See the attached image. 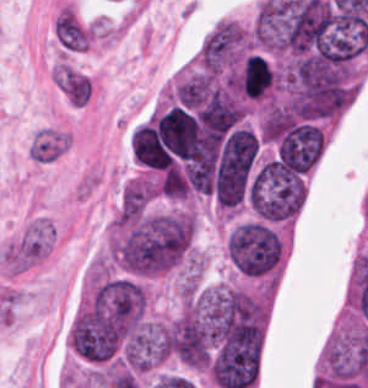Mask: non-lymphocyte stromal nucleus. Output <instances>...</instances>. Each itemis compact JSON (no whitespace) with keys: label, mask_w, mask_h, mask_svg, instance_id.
Masks as SVG:
<instances>
[{"label":"non-lymphocyte stromal nucleus","mask_w":368,"mask_h":388,"mask_svg":"<svg viewBox=\"0 0 368 388\" xmlns=\"http://www.w3.org/2000/svg\"><path fill=\"white\" fill-rule=\"evenodd\" d=\"M52 225L35 219L1 252L3 266L12 273H21L46 256L52 247Z\"/></svg>","instance_id":"dd21d789"},{"label":"non-lymphocyte stromal nucleus","mask_w":368,"mask_h":388,"mask_svg":"<svg viewBox=\"0 0 368 388\" xmlns=\"http://www.w3.org/2000/svg\"><path fill=\"white\" fill-rule=\"evenodd\" d=\"M57 80L65 95L74 104H85L92 94L89 75L65 64L56 65Z\"/></svg>","instance_id":"a72fc3eb"},{"label":"non-lymphocyte stromal nucleus","mask_w":368,"mask_h":388,"mask_svg":"<svg viewBox=\"0 0 368 388\" xmlns=\"http://www.w3.org/2000/svg\"><path fill=\"white\" fill-rule=\"evenodd\" d=\"M68 143V137L61 130L44 128L32 139L29 155L40 162L56 160Z\"/></svg>","instance_id":"3746e769"}]
</instances>
